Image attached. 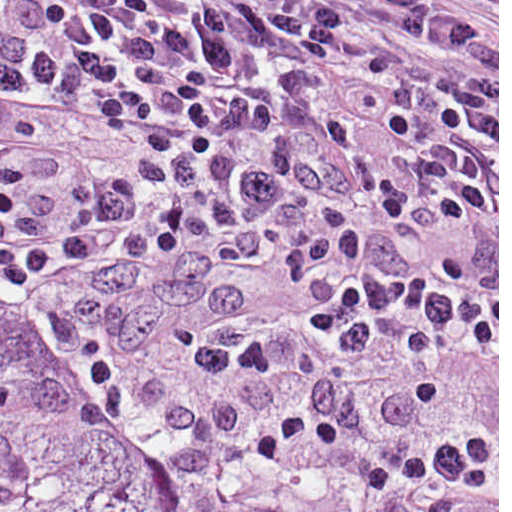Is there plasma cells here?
<instances>
[{
  "label": "plasma cells",
  "mask_w": 512,
  "mask_h": 512,
  "mask_svg": "<svg viewBox=\"0 0 512 512\" xmlns=\"http://www.w3.org/2000/svg\"><path fill=\"white\" fill-rule=\"evenodd\" d=\"M0 270L137 452L498 512V0H0Z\"/></svg>",
  "instance_id": "9512152a"
}]
</instances>
